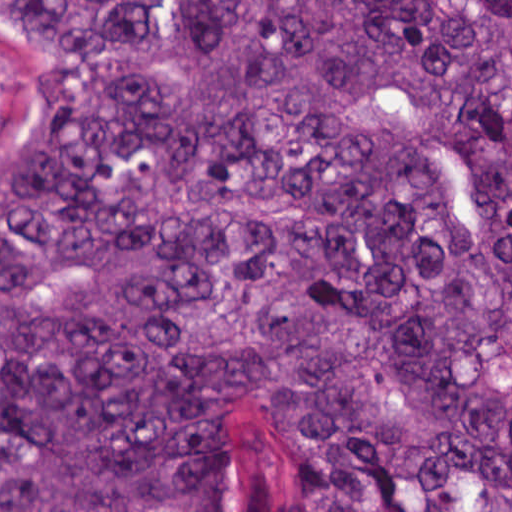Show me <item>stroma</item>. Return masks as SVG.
<instances>
[{
    "instance_id": "stroma-1",
    "label": "stroma",
    "mask_w": 512,
    "mask_h": 512,
    "mask_svg": "<svg viewBox=\"0 0 512 512\" xmlns=\"http://www.w3.org/2000/svg\"><path fill=\"white\" fill-rule=\"evenodd\" d=\"M68 68L66 46L0 14V170L51 114Z\"/></svg>"
}]
</instances>
